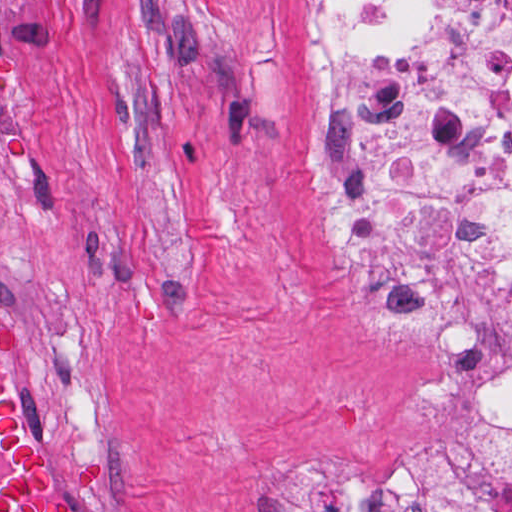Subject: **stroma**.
<instances>
[{"label":"stroma","mask_w":512,"mask_h":512,"mask_svg":"<svg viewBox=\"0 0 512 512\" xmlns=\"http://www.w3.org/2000/svg\"><path fill=\"white\" fill-rule=\"evenodd\" d=\"M311 5L0 0V329L26 342L3 366L74 512H247L282 456L393 489L443 460L464 379L328 260Z\"/></svg>","instance_id":"stroma-1"}]
</instances>
